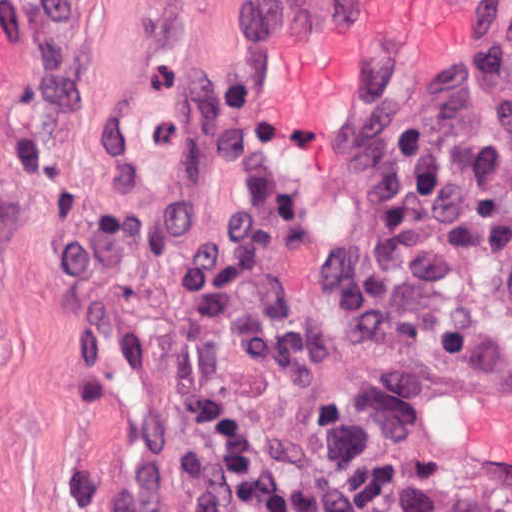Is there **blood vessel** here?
Listing matches in <instances>:
<instances>
[{
    "label": "blood vessel",
    "instance_id": "8fb6f2fc",
    "mask_svg": "<svg viewBox=\"0 0 512 512\" xmlns=\"http://www.w3.org/2000/svg\"><path fill=\"white\" fill-rule=\"evenodd\" d=\"M512 0H251L243 62L295 167L351 165L343 131L411 113L453 90ZM429 457L512 495V362L419 400Z\"/></svg>",
    "mask_w": 512,
    "mask_h": 512
}]
</instances>
